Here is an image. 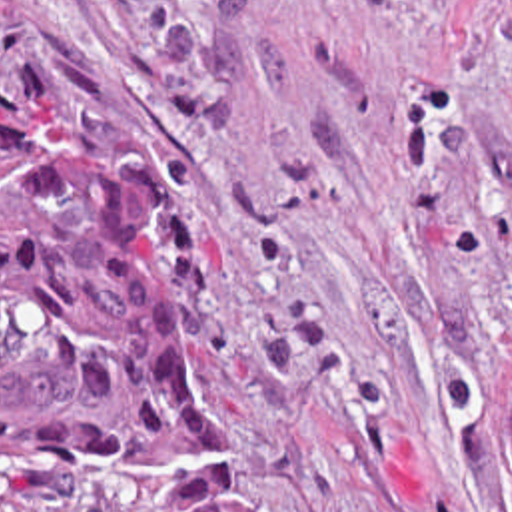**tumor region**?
Returning a JSON list of instances; mask_svg holds the SVG:
<instances>
[{"instance_id": "e687c5a6", "label": "tumor region", "mask_w": 512, "mask_h": 512, "mask_svg": "<svg viewBox=\"0 0 512 512\" xmlns=\"http://www.w3.org/2000/svg\"><path fill=\"white\" fill-rule=\"evenodd\" d=\"M498 478L512 500V386ZM0 512H266L132 208L1 85Z\"/></svg>"}]
</instances>
